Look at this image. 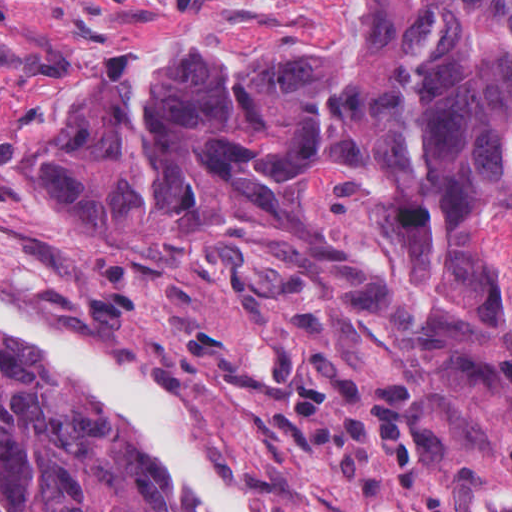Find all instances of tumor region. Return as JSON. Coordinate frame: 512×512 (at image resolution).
I'll use <instances>...</instances> for the list:
<instances>
[{"label":"tumor region","instance_id":"e687c5a6","mask_svg":"<svg viewBox=\"0 0 512 512\" xmlns=\"http://www.w3.org/2000/svg\"><path fill=\"white\" fill-rule=\"evenodd\" d=\"M187 110L209 111L232 139ZM341 126L377 127L398 150L417 251L405 246L448 308L482 320L494 286L463 228L476 196L512 186V0H380L367 37L301 24L233 67L165 54L140 82L128 43L113 47L38 187L99 237L237 202L353 300L381 291L377 276L322 241L308 186L403 243L388 199L352 167L319 166L306 185L271 164ZM0 512L193 511L102 397L0 337Z\"/></svg>","mask_w":512,"mask_h":512}]
</instances>
